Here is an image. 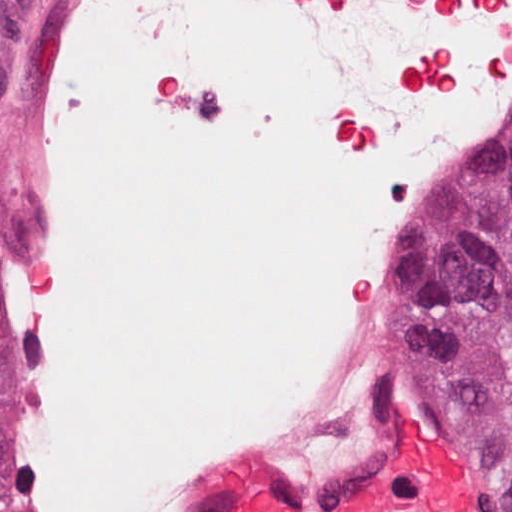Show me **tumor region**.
<instances>
[{"instance_id":"e687c5a6","label":"tumor region","mask_w":512,"mask_h":512,"mask_svg":"<svg viewBox=\"0 0 512 512\" xmlns=\"http://www.w3.org/2000/svg\"><path fill=\"white\" fill-rule=\"evenodd\" d=\"M10 198L0 171V249ZM431 355L509 475L512 512V142L467 207L428 286Z\"/></svg>"}]
</instances>
